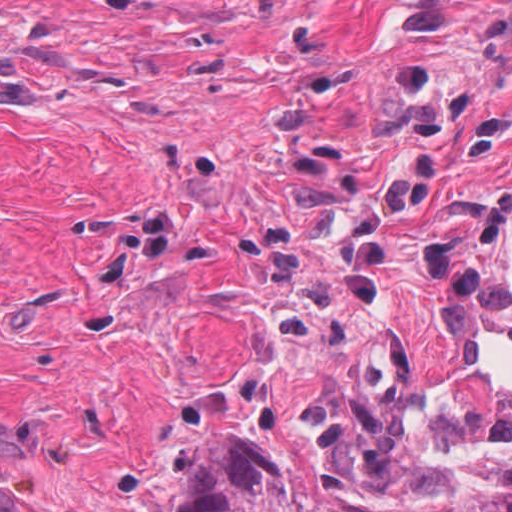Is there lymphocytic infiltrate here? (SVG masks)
<instances>
[{"label": "lymphocytic infiltrate", "instance_id": "1", "mask_svg": "<svg viewBox=\"0 0 512 512\" xmlns=\"http://www.w3.org/2000/svg\"><path fill=\"white\" fill-rule=\"evenodd\" d=\"M423 435L427 453H512V388H439Z\"/></svg>", "mask_w": 512, "mask_h": 512}]
</instances>
